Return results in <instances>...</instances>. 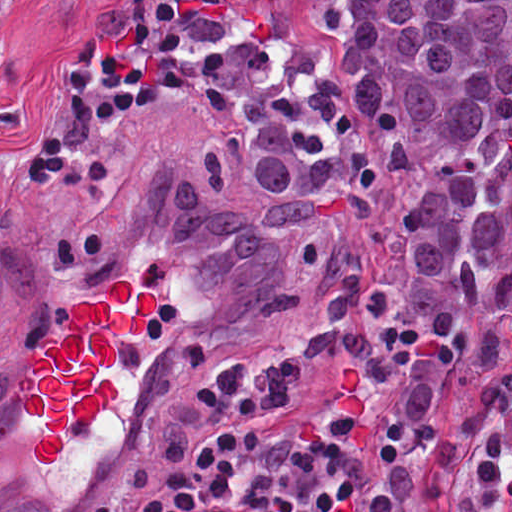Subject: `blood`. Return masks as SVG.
Masks as SVG:
<instances>
[{
  "mask_svg": "<svg viewBox=\"0 0 512 512\" xmlns=\"http://www.w3.org/2000/svg\"><path fill=\"white\" fill-rule=\"evenodd\" d=\"M157 306L156 290L136 292L128 280L119 279L101 302L87 299L74 305L70 335L47 338L41 349L28 354L30 367L20 375L19 388L26 413L45 427L31 445L40 464L54 463L70 428L89 427L115 402L118 380L99 381L96 375L114 365L115 334L140 333Z\"/></svg>",
  "mask_w": 512,
  "mask_h": 512,
  "instance_id": "obj_1",
  "label": "blood"
}]
</instances>
